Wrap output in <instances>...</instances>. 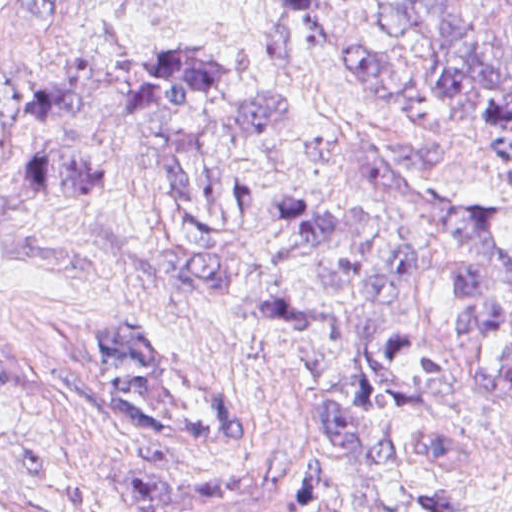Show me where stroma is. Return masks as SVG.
<instances>
[{
	"mask_svg": "<svg viewBox=\"0 0 512 512\" xmlns=\"http://www.w3.org/2000/svg\"><path fill=\"white\" fill-rule=\"evenodd\" d=\"M385 0H0V126L69 64L104 54L311 99L452 217L503 215L487 136L419 118L354 71ZM438 207V205H437ZM151 473L297 478L343 512H426L450 482L512 512V375L479 459L405 468L326 433L282 340L202 290L0 236V495L36 512H134Z\"/></svg>",
	"mask_w": 512,
	"mask_h": 512,
	"instance_id": "obj_1",
	"label": "stroma"
}]
</instances>
